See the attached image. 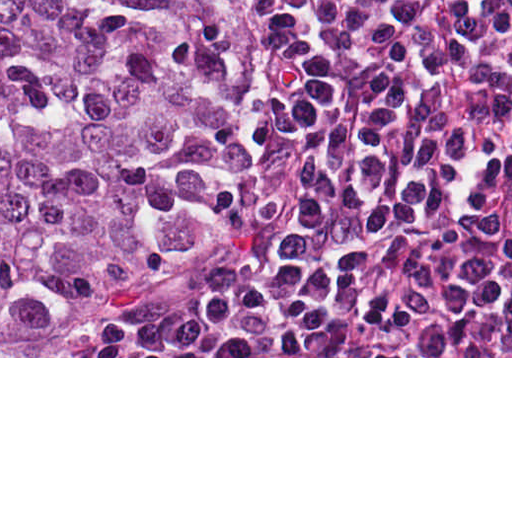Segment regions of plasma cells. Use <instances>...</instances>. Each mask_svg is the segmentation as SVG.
<instances>
[{
	"mask_svg": "<svg viewBox=\"0 0 512 512\" xmlns=\"http://www.w3.org/2000/svg\"><path fill=\"white\" fill-rule=\"evenodd\" d=\"M321 170L281 279L123 356H512V0H252Z\"/></svg>",
	"mask_w": 512,
	"mask_h": 512,
	"instance_id": "plasma-cells-1",
	"label": "plasma cells"
}]
</instances>
